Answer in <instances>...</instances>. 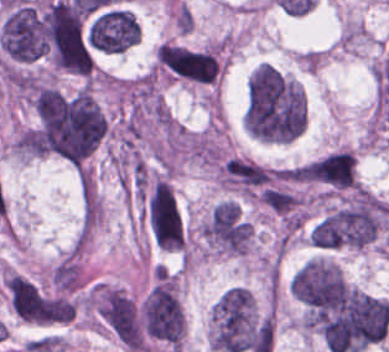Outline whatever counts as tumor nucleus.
Here are the masks:
<instances>
[{"mask_svg":"<svg viewBox=\"0 0 389 352\" xmlns=\"http://www.w3.org/2000/svg\"><path fill=\"white\" fill-rule=\"evenodd\" d=\"M38 118L47 147L69 163L84 159L106 129L98 103L83 90H41Z\"/></svg>","mask_w":389,"mask_h":352,"instance_id":"2f306a5c","label":"tumor nucleus"},{"mask_svg":"<svg viewBox=\"0 0 389 352\" xmlns=\"http://www.w3.org/2000/svg\"><path fill=\"white\" fill-rule=\"evenodd\" d=\"M243 126L255 137L292 138L302 127L299 87L268 63L257 65L246 83Z\"/></svg>","mask_w":389,"mask_h":352,"instance_id":"8643909e","label":"tumor nucleus"},{"mask_svg":"<svg viewBox=\"0 0 389 352\" xmlns=\"http://www.w3.org/2000/svg\"><path fill=\"white\" fill-rule=\"evenodd\" d=\"M43 25L54 66L86 75L93 60L79 9L65 2L53 1L43 15Z\"/></svg>","mask_w":389,"mask_h":352,"instance_id":"5ab6c2c4","label":"tumor nucleus"},{"mask_svg":"<svg viewBox=\"0 0 389 352\" xmlns=\"http://www.w3.org/2000/svg\"><path fill=\"white\" fill-rule=\"evenodd\" d=\"M383 211L380 201L358 199L317 221L310 238L317 247H364L375 240Z\"/></svg>","mask_w":389,"mask_h":352,"instance_id":"2cbd58db","label":"tumor nucleus"},{"mask_svg":"<svg viewBox=\"0 0 389 352\" xmlns=\"http://www.w3.org/2000/svg\"><path fill=\"white\" fill-rule=\"evenodd\" d=\"M347 289L338 266L326 260H306L291 277V293L314 317L332 312Z\"/></svg>","mask_w":389,"mask_h":352,"instance_id":"3d1891a8","label":"tumor nucleus"},{"mask_svg":"<svg viewBox=\"0 0 389 352\" xmlns=\"http://www.w3.org/2000/svg\"><path fill=\"white\" fill-rule=\"evenodd\" d=\"M255 323L248 290L232 287L213 308V348L241 352L248 345Z\"/></svg>","mask_w":389,"mask_h":352,"instance_id":"2083b535","label":"tumor nucleus"},{"mask_svg":"<svg viewBox=\"0 0 389 352\" xmlns=\"http://www.w3.org/2000/svg\"><path fill=\"white\" fill-rule=\"evenodd\" d=\"M0 46L16 61L38 59L47 51L43 17L26 3H19L4 16L0 27Z\"/></svg>","mask_w":389,"mask_h":352,"instance_id":"8087334f","label":"tumor nucleus"},{"mask_svg":"<svg viewBox=\"0 0 389 352\" xmlns=\"http://www.w3.org/2000/svg\"><path fill=\"white\" fill-rule=\"evenodd\" d=\"M141 330L152 338L180 343L182 308L171 281L160 279L140 306Z\"/></svg>","mask_w":389,"mask_h":352,"instance_id":"c2bd9aea","label":"tumor nucleus"},{"mask_svg":"<svg viewBox=\"0 0 389 352\" xmlns=\"http://www.w3.org/2000/svg\"><path fill=\"white\" fill-rule=\"evenodd\" d=\"M85 33L90 50L119 54L136 43L139 29L132 13L124 9H98Z\"/></svg>","mask_w":389,"mask_h":352,"instance_id":"feef74b5","label":"tumor nucleus"},{"mask_svg":"<svg viewBox=\"0 0 389 352\" xmlns=\"http://www.w3.org/2000/svg\"><path fill=\"white\" fill-rule=\"evenodd\" d=\"M145 221L151 237L165 248L182 241L181 215L168 184L152 183L146 203Z\"/></svg>","mask_w":389,"mask_h":352,"instance_id":"3e47fb67","label":"tumor nucleus"},{"mask_svg":"<svg viewBox=\"0 0 389 352\" xmlns=\"http://www.w3.org/2000/svg\"><path fill=\"white\" fill-rule=\"evenodd\" d=\"M98 316L125 348H139L142 332L132 301L123 293L105 288L99 294Z\"/></svg>","mask_w":389,"mask_h":352,"instance_id":"f7901128","label":"tumor nucleus"},{"mask_svg":"<svg viewBox=\"0 0 389 352\" xmlns=\"http://www.w3.org/2000/svg\"><path fill=\"white\" fill-rule=\"evenodd\" d=\"M162 67L176 76L207 83L218 74V60L206 50L176 45L162 44Z\"/></svg>","mask_w":389,"mask_h":352,"instance_id":"268c6acd","label":"tumor nucleus"},{"mask_svg":"<svg viewBox=\"0 0 389 352\" xmlns=\"http://www.w3.org/2000/svg\"><path fill=\"white\" fill-rule=\"evenodd\" d=\"M311 179L335 189L353 186V154L335 151L311 162Z\"/></svg>","mask_w":389,"mask_h":352,"instance_id":"1edb0cf7","label":"tumor nucleus"},{"mask_svg":"<svg viewBox=\"0 0 389 352\" xmlns=\"http://www.w3.org/2000/svg\"><path fill=\"white\" fill-rule=\"evenodd\" d=\"M260 196L264 204L276 212L287 214L296 204L293 194L281 189L264 187Z\"/></svg>","mask_w":389,"mask_h":352,"instance_id":"962dda3e","label":"tumor nucleus"}]
</instances>
